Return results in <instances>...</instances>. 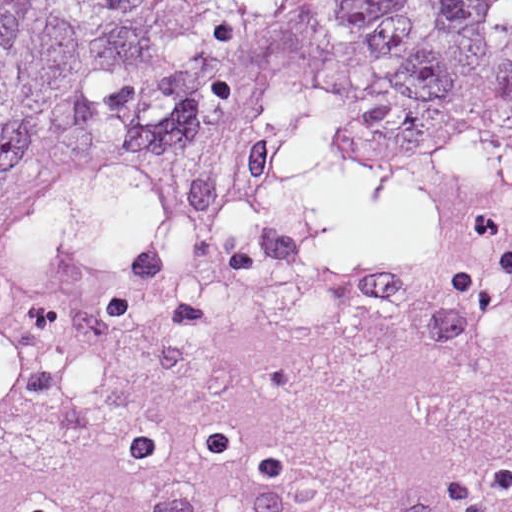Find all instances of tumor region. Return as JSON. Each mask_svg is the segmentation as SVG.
<instances>
[{
	"mask_svg": "<svg viewBox=\"0 0 512 512\" xmlns=\"http://www.w3.org/2000/svg\"><path fill=\"white\" fill-rule=\"evenodd\" d=\"M178 217L409 238L512 291V0H0V267Z\"/></svg>",
	"mask_w": 512,
	"mask_h": 512,
	"instance_id": "1",
	"label": "tumor region"
}]
</instances>
